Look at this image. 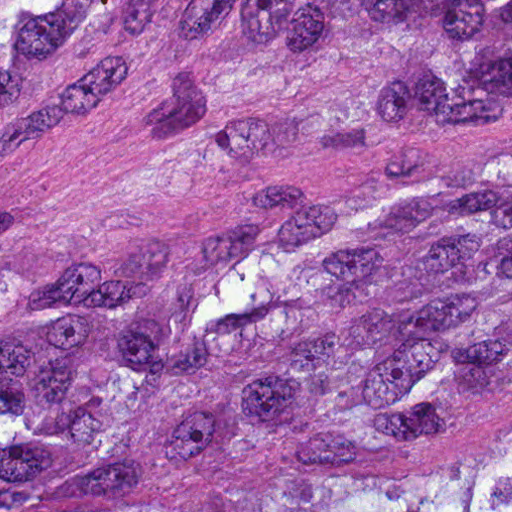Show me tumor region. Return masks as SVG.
I'll return each mask as SVG.
<instances>
[{
	"label": "tumor region",
	"instance_id": "e687c5a6",
	"mask_svg": "<svg viewBox=\"0 0 512 512\" xmlns=\"http://www.w3.org/2000/svg\"><path fill=\"white\" fill-rule=\"evenodd\" d=\"M318 163L194 232L0 247V512H512V0H0V153Z\"/></svg>",
	"mask_w": 512,
	"mask_h": 512
}]
</instances>
